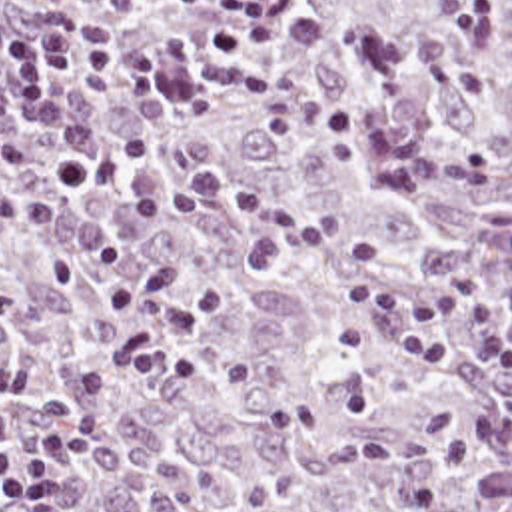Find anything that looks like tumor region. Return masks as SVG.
<instances>
[{"instance_id": "tumor-region-1", "label": "tumor region", "mask_w": 512, "mask_h": 512, "mask_svg": "<svg viewBox=\"0 0 512 512\" xmlns=\"http://www.w3.org/2000/svg\"><path fill=\"white\" fill-rule=\"evenodd\" d=\"M41 2L161 60L155 98L69 80L121 174L65 188L0 66V408L27 431L113 376L67 512H512V370L462 328L450 368L344 358L348 292L300 256L256 274L248 216L125 212L217 174L368 238L396 288H512V0H280L276 40L234 58L209 42L227 0Z\"/></svg>"}]
</instances>
